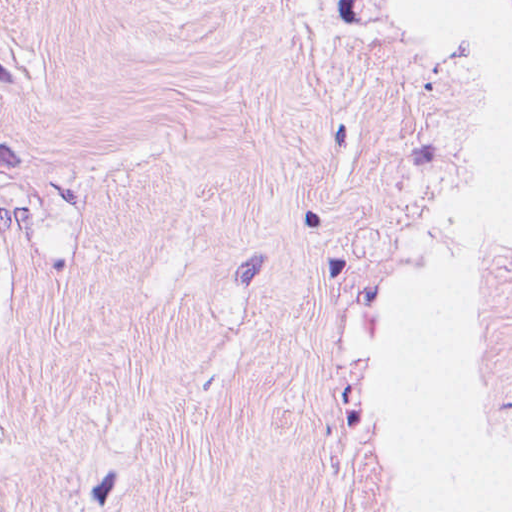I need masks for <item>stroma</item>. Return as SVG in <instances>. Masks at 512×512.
<instances>
[{
    "label": "stroma",
    "instance_id": "1",
    "mask_svg": "<svg viewBox=\"0 0 512 512\" xmlns=\"http://www.w3.org/2000/svg\"><path fill=\"white\" fill-rule=\"evenodd\" d=\"M439 222L410 0H0V512H412Z\"/></svg>",
    "mask_w": 512,
    "mask_h": 512
}]
</instances>
